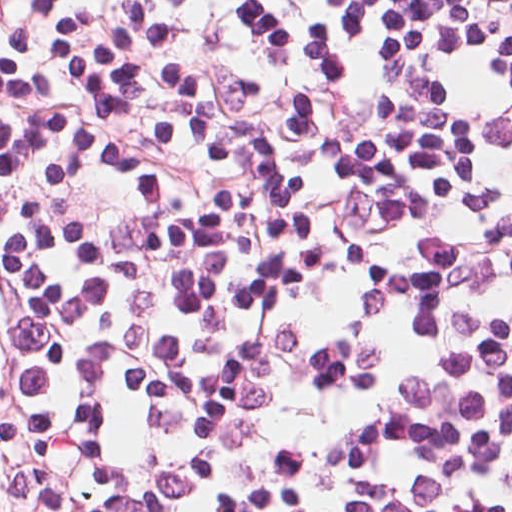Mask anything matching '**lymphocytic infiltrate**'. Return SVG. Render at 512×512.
I'll list each match as a JSON object with an SVG mask.
<instances>
[{"instance_id": "f902f5d3", "label": "lymphocytic infiltrate", "mask_w": 512, "mask_h": 512, "mask_svg": "<svg viewBox=\"0 0 512 512\" xmlns=\"http://www.w3.org/2000/svg\"><path fill=\"white\" fill-rule=\"evenodd\" d=\"M0 512H512V0H0Z\"/></svg>"}]
</instances>
